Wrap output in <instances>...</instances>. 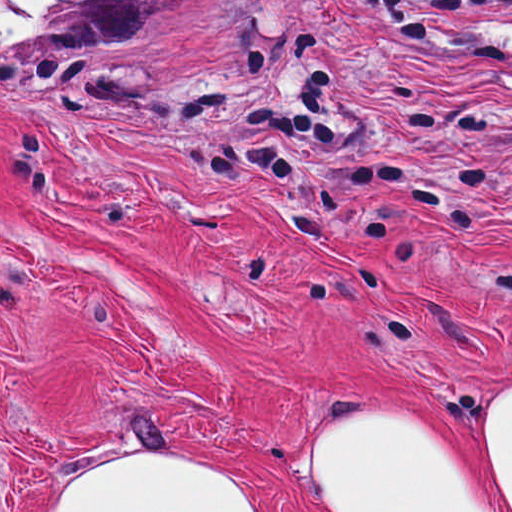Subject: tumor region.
I'll return each instance as SVG.
<instances>
[{"label":"tumor region","instance_id":"e687c5a6","mask_svg":"<svg viewBox=\"0 0 512 512\" xmlns=\"http://www.w3.org/2000/svg\"><path fill=\"white\" fill-rule=\"evenodd\" d=\"M215 0H0V59L151 42Z\"/></svg>","mask_w":512,"mask_h":512}]
</instances>
